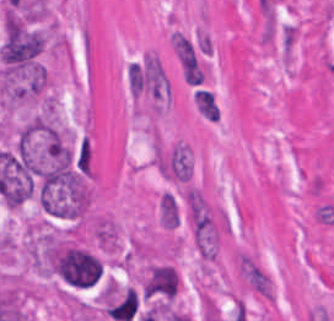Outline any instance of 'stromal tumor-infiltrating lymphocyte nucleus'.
I'll use <instances>...</instances> for the list:
<instances>
[{"instance_id":"1","label":"stromal tumor-infiltrating lymphocyte nucleus","mask_w":334,"mask_h":321,"mask_svg":"<svg viewBox=\"0 0 334 321\" xmlns=\"http://www.w3.org/2000/svg\"><path fill=\"white\" fill-rule=\"evenodd\" d=\"M194 101L200 115L210 121H217L220 118L219 106L214 91L209 89H195Z\"/></svg>"}]
</instances>
